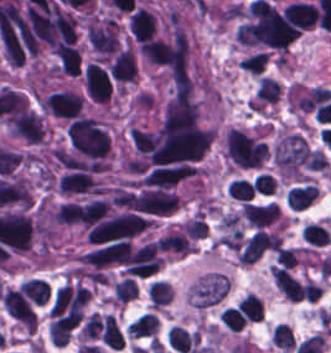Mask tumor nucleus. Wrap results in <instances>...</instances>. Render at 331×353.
Here are the masks:
<instances>
[{"mask_svg": "<svg viewBox=\"0 0 331 353\" xmlns=\"http://www.w3.org/2000/svg\"><path fill=\"white\" fill-rule=\"evenodd\" d=\"M223 151L240 168H258L269 155L264 142L236 127L224 133Z\"/></svg>", "mask_w": 331, "mask_h": 353, "instance_id": "1", "label": "tumor nucleus"}, {"mask_svg": "<svg viewBox=\"0 0 331 353\" xmlns=\"http://www.w3.org/2000/svg\"><path fill=\"white\" fill-rule=\"evenodd\" d=\"M119 25L115 17H95L84 30L89 49L97 59H105L117 50Z\"/></svg>", "mask_w": 331, "mask_h": 353, "instance_id": "2", "label": "tumor nucleus"}, {"mask_svg": "<svg viewBox=\"0 0 331 353\" xmlns=\"http://www.w3.org/2000/svg\"><path fill=\"white\" fill-rule=\"evenodd\" d=\"M82 103L83 97L78 91L61 89L43 96L41 108L52 116L69 119L78 116Z\"/></svg>", "mask_w": 331, "mask_h": 353, "instance_id": "3", "label": "tumor nucleus"}, {"mask_svg": "<svg viewBox=\"0 0 331 353\" xmlns=\"http://www.w3.org/2000/svg\"><path fill=\"white\" fill-rule=\"evenodd\" d=\"M82 85L86 97L104 107L107 105L111 97L110 80L93 61L84 65Z\"/></svg>", "mask_w": 331, "mask_h": 353, "instance_id": "4", "label": "tumor nucleus"}, {"mask_svg": "<svg viewBox=\"0 0 331 353\" xmlns=\"http://www.w3.org/2000/svg\"><path fill=\"white\" fill-rule=\"evenodd\" d=\"M128 29L130 36L140 43L151 39L156 30V16L137 7L130 14Z\"/></svg>", "mask_w": 331, "mask_h": 353, "instance_id": "5", "label": "tumor nucleus"}, {"mask_svg": "<svg viewBox=\"0 0 331 353\" xmlns=\"http://www.w3.org/2000/svg\"><path fill=\"white\" fill-rule=\"evenodd\" d=\"M239 209L248 226L280 216L278 207L274 202L243 200L239 204Z\"/></svg>", "mask_w": 331, "mask_h": 353, "instance_id": "6", "label": "tumor nucleus"}]
</instances>
